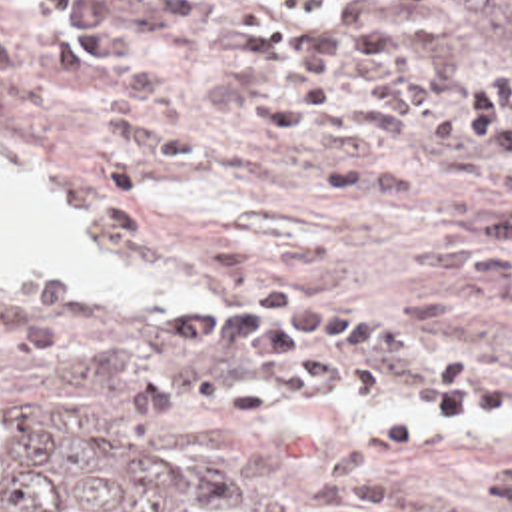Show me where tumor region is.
<instances>
[{"label":"tumor region","instance_id":"tumor-region-1","mask_svg":"<svg viewBox=\"0 0 512 512\" xmlns=\"http://www.w3.org/2000/svg\"><path fill=\"white\" fill-rule=\"evenodd\" d=\"M450 51L512 55V0H424ZM0 512H206L87 434L55 394L0 380Z\"/></svg>","mask_w":512,"mask_h":512}]
</instances>
